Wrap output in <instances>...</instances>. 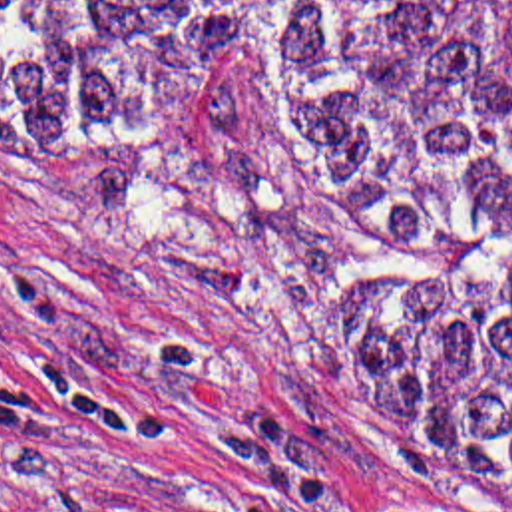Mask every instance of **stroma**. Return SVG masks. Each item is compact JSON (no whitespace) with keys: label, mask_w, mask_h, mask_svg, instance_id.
Here are the masks:
<instances>
[{"label":"stroma","mask_w":512,"mask_h":512,"mask_svg":"<svg viewBox=\"0 0 512 512\" xmlns=\"http://www.w3.org/2000/svg\"><path fill=\"white\" fill-rule=\"evenodd\" d=\"M391 288L261 61L166 131L0 119V512H512L377 469L347 362Z\"/></svg>","instance_id":"obj_1"}]
</instances>
